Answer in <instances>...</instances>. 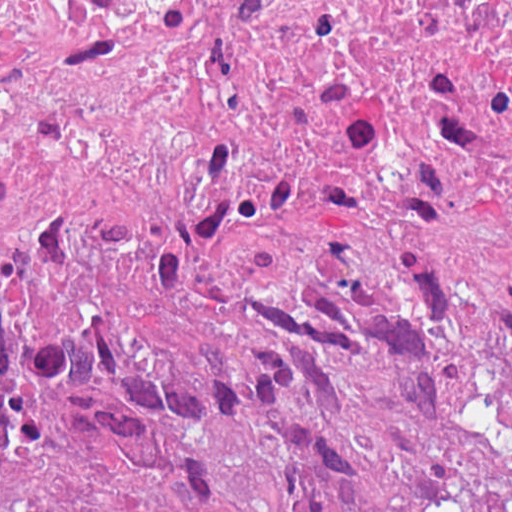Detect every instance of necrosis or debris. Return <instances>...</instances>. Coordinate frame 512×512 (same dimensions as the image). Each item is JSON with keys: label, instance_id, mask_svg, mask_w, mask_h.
<instances>
[{"label": "necrosis or debris", "instance_id": "4bbe7bcc", "mask_svg": "<svg viewBox=\"0 0 512 512\" xmlns=\"http://www.w3.org/2000/svg\"><path fill=\"white\" fill-rule=\"evenodd\" d=\"M512 120V0H1L0 190L100 182L193 225L264 177Z\"/></svg>", "mask_w": 512, "mask_h": 512}]
</instances>
